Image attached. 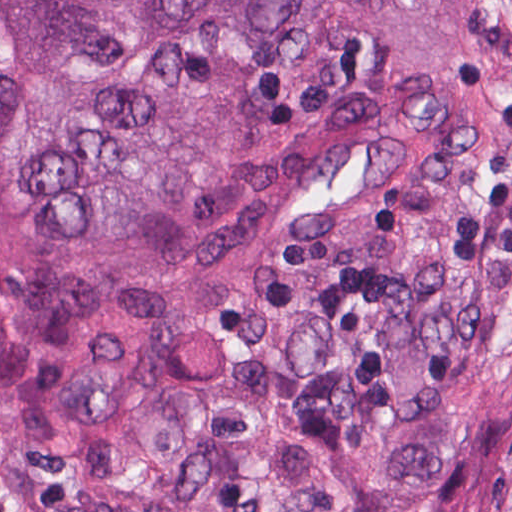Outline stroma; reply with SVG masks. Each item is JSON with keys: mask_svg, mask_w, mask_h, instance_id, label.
I'll use <instances>...</instances> for the list:
<instances>
[{"mask_svg": "<svg viewBox=\"0 0 512 512\" xmlns=\"http://www.w3.org/2000/svg\"><path fill=\"white\" fill-rule=\"evenodd\" d=\"M400 0H395L268 512H288Z\"/></svg>", "mask_w": 512, "mask_h": 512, "instance_id": "obj_1", "label": "stroma"}]
</instances>
